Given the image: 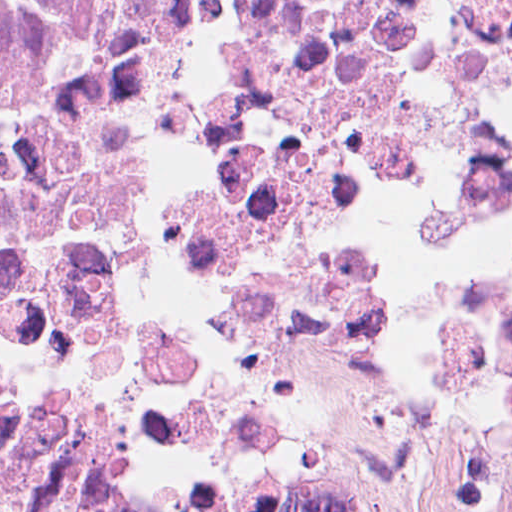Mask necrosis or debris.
<instances>
[{
	"label": "necrosis or debris",
	"mask_w": 512,
	"mask_h": 512,
	"mask_svg": "<svg viewBox=\"0 0 512 512\" xmlns=\"http://www.w3.org/2000/svg\"><path fill=\"white\" fill-rule=\"evenodd\" d=\"M91 404L512 512V0H0V440Z\"/></svg>",
	"instance_id": "necrosis-or-debris-1"
}]
</instances>
